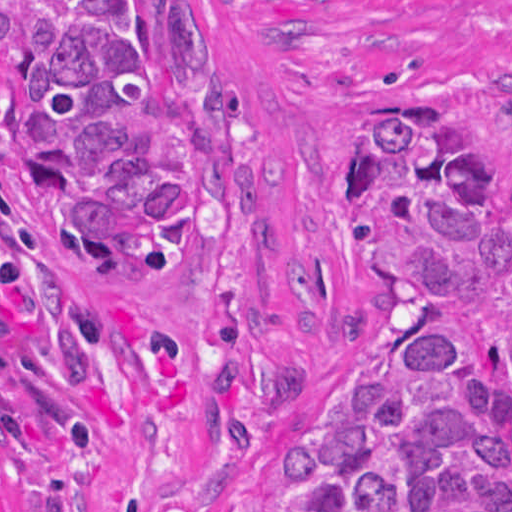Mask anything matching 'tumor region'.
I'll use <instances>...</instances> for the list:
<instances>
[{"instance_id": "obj_1", "label": "tumor region", "mask_w": 512, "mask_h": 512, "mask_svg": "<svg viewBox=\"0 0 512 512\" xmlns=\"http://www.w3.org/2000/svg\"><path fill=\"white\" fill-rule=\"evenodd\" d=\"M217 181L191 0H0V420L51 512L125 447L120 270H193ZM345 198L374 342L293 435L266 512H512V134L477 161L380 107Z\"/></svg>"}]
</instances>
